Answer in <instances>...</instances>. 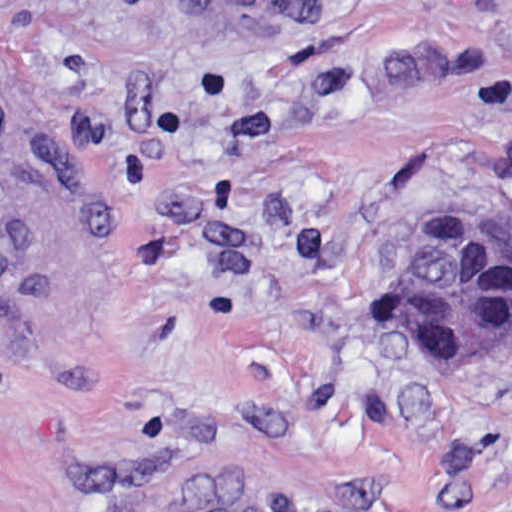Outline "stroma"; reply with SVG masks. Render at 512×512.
Masks as SVG:
<instances>
[{
    "label": "stroma",
    "mask_w": 512,
    "mask_h": 512,
    "mask_svg": "<svg viewBox=\"0 0 512 512\" xmlns=\"http://www.w3.org/2000/svg\"><path fill=\"white\" fill-rule=\"evenodd\" d=\"M0 512H512V343L391 294L512 237V0H0Z\"/></svg>",
    "instance_id": "obj_1"
}]
</instances>
